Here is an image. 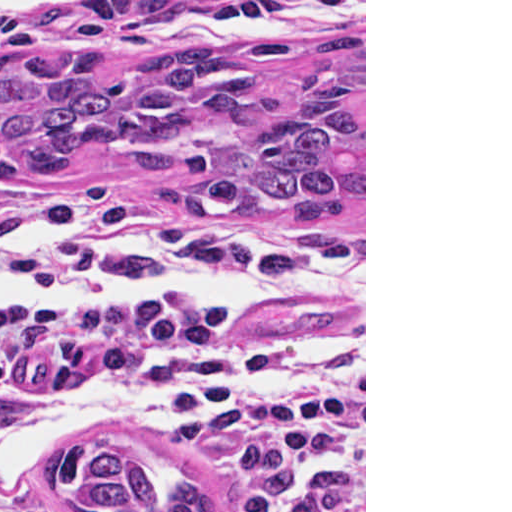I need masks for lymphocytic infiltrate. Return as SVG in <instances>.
Listing matches in <instances>:
<instances>
[{"label":"lymphocytic infiltrate","instance_id":"f902f5d3","mask_svg":"<svg viewBox=\"0 0 512 512\" xmlns=\"http://www.w3.org/2000/svg\"><path fill=\"white\" fill-rule=\"evenodd\" d=\"M83 333L158 347L166 362L257 338L244 311L217 300H99L31 312L0 327V430L7 401L32 363ZM172 404L202 433L223 512H274L324 451L333 424L332 394L321 385L256 410L229 393L227 375L212 363ZM0 512L68 511L0 484Z\"/></svg>","mask_w":512,"mask_h":512}]
</instances>
